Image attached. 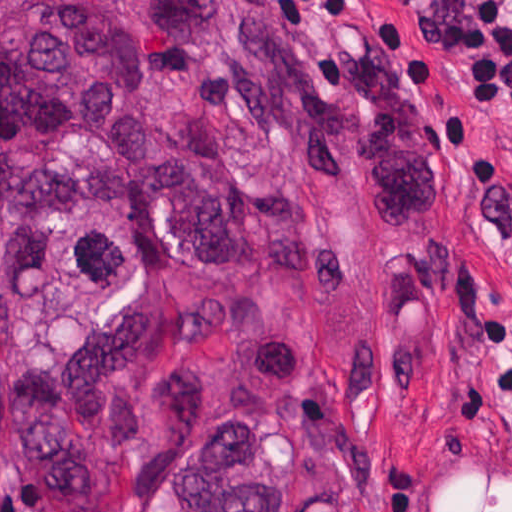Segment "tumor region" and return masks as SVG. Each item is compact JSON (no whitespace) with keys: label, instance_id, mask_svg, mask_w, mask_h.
Wrapping results in <instances>:
<instances>
[{"label":"tumor region","instance_id":"1","mask_svg":"<svg viewBox=\"0 0 512 512\" xmlns=\"http://www.w3.org/2000/svg\"><path fill=\"white\" fill-rule=\"evenodd\" d=\"M434 201L393 47L314 72L275 0H0V464L123 512H397L387 236Z\"/></svg>","mask_w":512,"mask_h":512}]
</instances>
